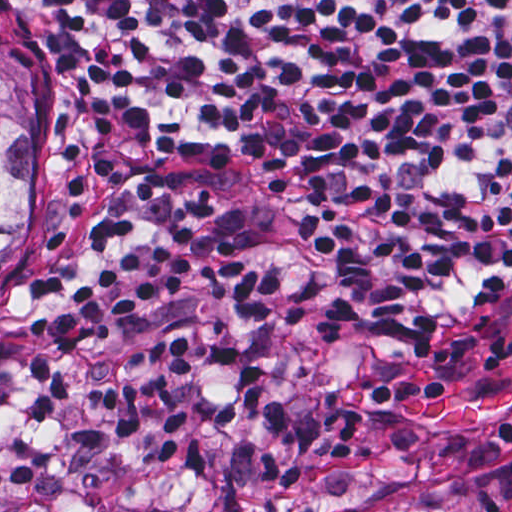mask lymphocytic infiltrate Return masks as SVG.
I'll return each instance as SVG.
<instances>
[{"mask_svg": "<svg viewBox=\"0 0 512 512\" xmlns=\"http://www.w3.org/2000/svg\"><path fill=\"white\" fill-rule=\"evenodd\" d=\"M70 40L94 93L160 148L276 190L347 263L374 329L410 341L512 280V0H31ZM133 194L177 223L135 242L130 217L92 223L106 267L28 330L29 420H59L89 389L122 436L161 460L185 419L171 377L208 362L237 388L221 428L249 425L292 451L270 371L219 337L165 333L129 353L127 380L75 365L201 280L206 300L271 323L285 288L210 222V187L152 169Z\"/></svg>", "mask_w": 512, "mask_h": 512, "instance_id": "lymphocytic-infiltrate-1", "label": "lymphocytic infiltrate"}]
</instances>
